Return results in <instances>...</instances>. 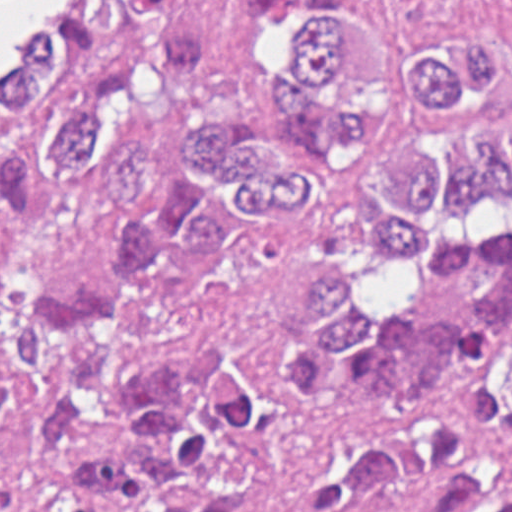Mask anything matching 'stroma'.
<instances>
[{
	"label": "stroma",
	"instance_id": "1",
	"mask_svg": "<svg viewBox=\"0 0 512 512\" xmlns=\"http://www.w3.org/2000/svg\"><path fill=\"white\" fill-rule=\"evenodd\" d=\"M69 1L63 14L36 25L18 49L15 70H0V133L32 127L43 71L85 19L108 1H205L216 25L209 70L190 77L200 97L232 100L246 56L240 44L243 14L255 3L286 11L300 1H347L365 32L402 39L478 36L512 72V0H0ZM109 215L99 200L54 185L40 229L10 278H77L98 274L106 256ZM488 471L512 482V438L499 447Z\"/></svg>",
	"mask_w": 512,
	"mask_h": 512
}]
</instances>
